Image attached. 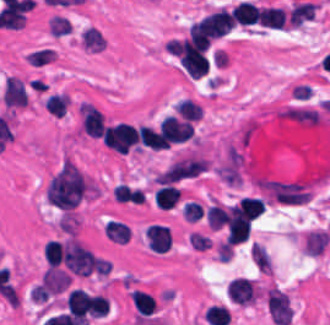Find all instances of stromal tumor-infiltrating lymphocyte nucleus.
Returning <instances> with one entry per match:
<instances>
[{"label":"stromal tumor-infiltrating lymphocyte nucleus","instance_id":"bc302bb0","mask_svg":"<svg viewBox=\"0 0 330 325\" xmlns=\"http://www.w3.org/2000/svg\"><path fill=\"white\" fill-rule=\"evenodd\" d=\"M103 143L110 149L126 153L137 145L135 128L126 121L106 125L102 131Z\"/></svg>","mask_w":330,"mask_h":325},{"label":"stromal tumor-infiltrating lymphocyte nucleus","instance_id":"52c7bb5b","mask_svg":"<svg viewBox=\"0 0 330 325\" xmlns=\"http://www.w3.org/2000/svg\"><path fill=\"white\" fill-rule=\"evenodd\" d=\"M265 299L271 321L288 325L291 321V308L285 292L276 286H269L265 291Z\"/></svg>","mask_w":330,"mask_h":325},{"label":"stromal tumor-infiltrating lymphocyte nucleus","instance_id":"3290ff9b","mask_svg":"<svg viewBox=\"0 0 330 325\" xmlns=\"http://www.w3.org/2000/svg\"><path fill=\"white\" fill-rule=\"evenodd\" d=\"M251 218L233 207L226 210L225 232L227 243H236L247 237L250 230Z\"/></svg>","mask_w":330,"mask_h":325},{"label":"stromal tumor-infiltrating lymphocyte nucleus","instance_id":"abfb95fc","mask_svg":"<svg viewBox=\"0 0 330 325\" xmlns=\"http://www.w3.org/2000/svg\"><path fill=\"white\" fill-rule=\"evenodd\" d=\"M167 140L185 141L191 136L193 124L189 119L166 115L157 125Z\"/></svg>","mask_w":330,"mask_h":325},{"label":"stromal tumor-infiltrating lymphocyte nucleus","instance_id":"9ea309e8","mask_svg":"<svg viewBox=\"0 0 330 325\" xmlns=\"http://www.w3.org/2000/svg\"><path fill=\"white\" fill-rule=\"evenodd\" d=\"M0 99L7 106H23L28 99L23 81L17 76L7 75L1 89Z\"/></svg>","mask_w":330,"mask_h":325},{"label":"stromal tumor-infiltrating lymphocyte nucleus","instance_id":"f3e2335f","mask_svg":"<svg viewBox=\"0 0 330 325\" xmlns=\"http://www.w3.org/2000/svg\"><path fill=\"white\" fill-rule=\"evenodd\" d=\"M79 114L82 131L86 135L100 137L104 118L99 109L89 101H82L79 105Z\"/></svg>","mask_w":330,"mask_h":325},{"label":"stromal tumor-infiltrating lymphocyte nucleus","instance_id":"4f13568d","mask_svg":"<svg viewBox=\"0 0 330 325\" xmlns=\"http://www.w3.org/2000/svg\"><path fill=\"white\" fill-rule=\"evenodd\" d=\"M227 294L238 304H247L255 300L254 281L244 275H237L227 284Z\"/></svg>","mask_w":330,"mask_h":325},{"label":"stromal tumor-infiltrating lymphocyte nucleus","instance_id":"2a367800","mask_svg":"<svg viewBox=\"0 0 330 325\" xmlns=\"http://www.w3.org/2000/svg\"><path fill=\"white\" fill-rule=\"evenodd\" d=\"M329 234L319 227L308 228L302 237V247L306 255H318L328 244Z\"/></svg>","mask_w":330,"mask_h":325},{"label":"stromal tumor-infiltrating lymphocyte nucleus","instance_id":"4803ca6d","mask_svg":"<svg viewBox=\"0 0 330 325\" xmlns=\"http://www.w3.org/2000/svg\"><path fill=\"white\" fill-rule=\"evenodd\" d=\"M265 204L261 198L255 196H242L233 206V215L247 218H257L263 211Z\"/></svg>","mask_w":330,"mask_h":325},{"label":"stromal tumor-infiltrating lymphocyte nucleus","instance_id":"4245b91a","mask_svg":"<svg viewBox=\"0 0 330 325\" xmlns=\"http://www.w3.org/2000/svg\"><path fill=\"white\" fill-rule=\"evenodd\" d=\"M286 12L280 6H260L258 11V24L269 28H283Z\"/></svg>","mask_w":330,"mask_h":325},{"label":"stromal tumor-infiltrating lymphocyte nucleus","instance_id":"4c9ddf68","mask_svg":"<svg viewBox=\"0 0 330 325\" xmlns=\"http://www.w3.org/2000/svg\"><path fill=\"white\" fill-rule=\"evenodd\" d=\"M180 196V188L169 183H162L153 193V201L162 210H169Z\"/></svg>","mask_w":330,"mask_h":325},{"label":"stromal tumor-infiltrating lymphocyte nucleus","instance_id":"2761f720","mask_svg":"<svg viewBox=\"0 0 330 325\" xmlns=\"http://www.w3.org/2000/svg\"><path fill=\"white\" fill-rule=\"evenodd\" d=\"M136 135L141 145L150 149H161L169 146L161 132L146 124L137 126Z\"/></svg>","mask_w":330,"mask_h":325},{"label":"stromal tumor-infiltrating lymphocyte nucleus","instance_id":"3c572f05","mask_svg":"<svg viewBox=\"0 0 330 325\" xmlns=\"http://www.w3.org/2000/svg\"><path fill=\"white\" fill-rule=\"evenodd\" d=\"M314 10V2L296 1L289 9L287 22L291 27H299L313 17Z\"/></svg>","mask_w":330,"mask_h":325},{"label":"stromal tumor-infiltrating lymphocyte nucleus","instance_id":"42bb06b2","mask_svg":"<svg viewBox=\"0 0 330 325\" xmlns=\"http://www.w3.org/2000/svg\"><path fill=\"white\" fill-rule=\"evenodd\" d=\"M259 7L253 1H239L232 9L233 21L241 24H253L258 17Z\"/></svg>","mask_w":330,"mask_h":325},{"label":"stromal tumor-infiltrating lymphocyte nucleus","instance_id":"9e4306bb","mask_svg":"<svg viewBox=\"0 0 330 325\" xmlns=\"http://www.w3.org/2000/svg\"><path fill=\"white\" fill-rule=\"evenodd\" d=\"M129 297L137 314H151L156 308V298L148 292L133 288Z\"/></svg>","mask_w":330,"mask_h":325},{"label":"stromal tumor-infiltrating lymphocyte nucleus","instance_id":"04cf8593","mask_svg":"<svg viewBox=\"0 0 330 325\" xmlns=\"http://www.w3.org/2000/svg\"><path fill=\"white\" fill-rule=\"evenodd\" d=\"M103 232L106 238L115 243H125L130 233L126 223L110 218L104 222Z\"/></svg>","mask_w":330,"mask_h":325},{"label":"stromal tumor-infiltrating lymphocyte nucleus","instance_id":"e9af9c67","mask_svg":"<svg viewBox=\"0 0 330 325\" xmlns=\"http://www.w3.org/2000/svg\"><path fill=\"white\" fill-rule=\"evenodd\" d=\"M174 109L180 118L195 121L200 119L201 105L185 97L178 99Z\"/></svg>","mask_w":330,"mask_h":325},{"label":"stromal tumor-infiltrating lymphocyte nucleus","instance_id":"782c7336","mask_svg":"<svg viewBox=\"0 0 330 325\" xmlns=\"http://www.w3.org/2000/svg\"><path fill=\"white\" fill-rule=\"evenodd\" d=\"M82 48L100 50L104 45L103 34L95 26L89 25L81 34Z\"/></svg>","mask_w":330,"mask_h":325},{"label":"stromal tumor-infiltrating lymphocyte nucleus","instance_id":"cac63f63","mask_svg":"<svg viewBox=\"0 0 330 325\" xmlns=\"http://www.w3.org/2000/svg\"><path fill=\"white\" fill-rule=\"evenodd\" d=\"M68 104L66 92H53L43 101L44 108L52 115H62Z\"/></svg>","mask_w":330,"mask_h":325},{"label":"stromal tumor-infiltrating lymphocyte nucleus","instance_id":"2e467ee5","mask_svg":"<svg viewBox=\"0 0 330 325\" xmlns=\"http://www.w3.org/2000/svg\"><path fill=\"white\" fill-rule=\"evenodd\" d=\"M249 251L257 270L270 274L271 263L264 247L260 243L252 241L250 242Z\"/></svg>","mask_w":330,"mask_h":325},{"label":"stromal tumor-infiltrating lymphocyte nucleus","instance_id":"7eef579d","mask_svg":"<svg viewBox=\"0 0 330 325\" xmlns=\"http://www.w3.org/2000/svg\"><path fill=\"white\" fill-rule=\"evenodd\" d=\"M206 222L210 228L221 227L227 219L226 210L222 205L210 204L205 212Z\"/></svg>","mask_w":330,"mask_h":325},{"label":"stromal tumor-infiltrating lymphocyte nucleus","instance_id":"c26a33f6","mask_svg":"<svg viewBox=\"0 0 330 325\" xmlns=\"http://www.w3.org/2000/svg\"><path fill=\"white\" fill-rule=\"evenodd\" d=\"M43 254L47 265H59L62 257V245L55 239H48L43 245Z\"/></svg>","mask_w":330,"mask_h":325},{"label":"stromal tumor-infiltrating lymphocyte nucleus","instance_id":"3e0999b9","mask_svg":"<svg viewBox=\"0 0 330 325\" xmlns=\"http://www.w3.org/2000/svg\"><path fill=\"white\" fill-rule=\"evenodd\" d=\"M48 32L52 35H60L70 32L72 26L65 16L53 14L48 20L47 24Z\"/></svg>","mask_w":330,"mask_h":325}]
</instances>
